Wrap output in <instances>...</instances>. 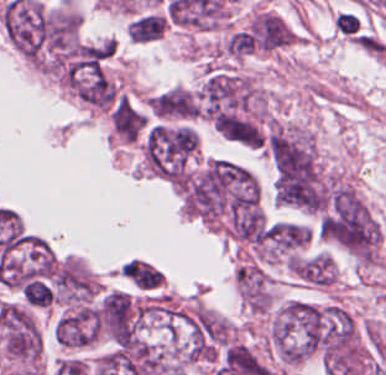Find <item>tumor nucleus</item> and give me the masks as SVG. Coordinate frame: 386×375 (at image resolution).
<instances>
[{"label":"tumor nucleus","mask_w":386,"mask_h":375,"mask_svg":"<svg viewBox=\"0 0 386 375\" xmlns=\"http://www.w3.org/2000/svg\"><path fill=\"white\" fill-rule=\"evenodd\" d=\"M195 110L211 121L258 116L264 111V95L247 72L210 67Z\"/></svg>","instance_id":"2f306a5c"},{"label":"tumor nucleus","mask_w":386,"mask_h":375,"mask_svg":"<svg viewBox=\"0 0 386 375\" xmlns=\"http://www.w3.org/2000/svg\"><path fill=\"white\" fill-rule=\"evenodd\" d=\"M100 311L91 304L67 310L55 322L57 344L86 346L99 336Z\"/></svg>","instance_id":"8643909e"},{"label":"tumor nucleus","mask_w":386,"mask_h":375,"mask_svg":"<svg viewBox=\"0 0 386 375\" xmlns=\"http://www.w3.org/2000/svg\"><path fill=\"white\" fill-rule=\"evenodd\" d=\"M155 118L187 121L197 116L198 95L184 86H170L148 100Z\"/></svg>","instance_id":"5ab6c2c4"},{"label":"tumor nucleus","mask_w":386,"mask_h":375,"mask_svg":"<svg viewBox=\"0 0 386 375\" xmlns=\"http://www.w3.org/2000/svg\"><path fill=\"white\" fill-rule=\"evenodd\" d=\"M238 294L245 305L270 307L272 294L268 273L257 263L245 261L237 268Z\"/></svg>","instance_id":"2cbd58db"},{"label":"tumor nucleus","mask_w":386,"mask_h":375,"mask_svg":"<svg viewBox=\"0 0 386 375\" xmlns=\"http://www.w3.org/2000/svg\"><path fill=\"white\" fill-rule=\"evenodd\" d=\"M259 47L275 48L290 42V33L282 18L273 13H259L248 26Z\"/></svg>","instance_id":"3d1891a8"}]
</instances>
